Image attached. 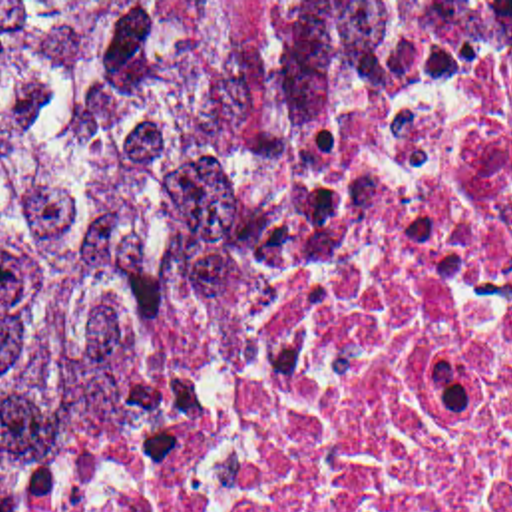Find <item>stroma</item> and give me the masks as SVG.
<instances>
[{
	"label": "stroma",
	"instance_id": "35a3bbf8",
	"mask_svg": "<svg viewBox=\"0 0 512 512\" xmlns=\"http://www.w3.org/2000/svg\"><path fill=\"white\" fill-rule=\"evenodd\" d=\"M0 2H512V0H0ZM487 34H512V30H493V32H487ZM416 84V82H414ZM412 84V86H414ZM410 86V88H412ZM410 88H406L404 92H400L396 98H392L388 104H384V106H380V108H376V110H372L366 118L362 119L348 135H352V133H356V131H360V129H364L370 121H374V119L378 118L382 112H386L394 102H398ZM346 135V137H348ZM61 438V436H59ZM59 438H55L53 442H49L47 446H43L39 452H35L27 462H23L3 484L0 486V498L59 440Z\"/></svg>",
	"mask_w": 512,
	"mask_h": 512
}]
</instances>
